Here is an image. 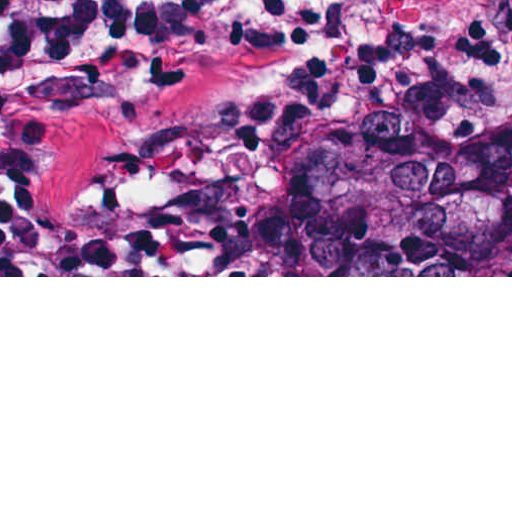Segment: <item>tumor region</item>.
I'll use <instances>...</instances> for the list:
<instances>
[{
  "label": "tumor region",
  "instance_id": "1",
  "mask_svg": "<svg viewBox=\"0 0 512 512\" xmlns=\"http://www.w3.org/2000/svg\"><path fill=\"white\" fill-rule=\"evenodd\" d=\"M395 0H357L309 42H363ZM72 106L40 157L52 214L165 238L172 275H510L512 142L386 117L324 144L174 126L212 62Z\"/></svg>",
  "mask_w": 512,
  "mask_h": 512
}]
</instances>
